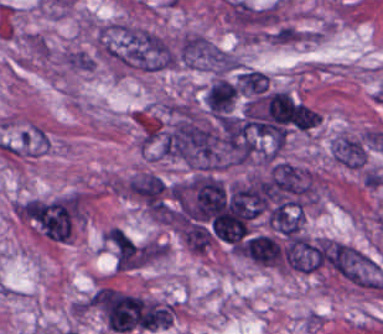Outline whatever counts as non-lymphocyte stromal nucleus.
<instances>
[{
	"label": "non-lymphocyte stromal nucleus",
	"instance_id": "a72fc3eb",
	"mask_svg": "<svg viewBox=\"0 0 383 334\" xmlns=\"http://www.w3.org/2000/svg\"><path fill=\"white\" fill-rule=\"evenodd\" d=\"M323 250L328 268L350 284L381 288L383 276L376 262L356 246L326 238Z\"/></svg>",
	"mask_w": 383,
	"mask_h": 334
},
{
	"label": "non-lymphocyte stromal nucleus",
	"instance_id": "fc2b8d12",
	"mask_svg": "<svg viewBox=\"0 0 383 334\" xmlns=\"http://www.w3.org/2000/svg\"><path fill=\"white\" fill-rule=\"evenodd\" d=\"M66 67L76 71H90L94 66V57L84 51L71 50L64 55Z\"/></svg>",
	"mask_w": 383,
	"mask_h": 334
},
{
	"label": "non-lymphocyte stromal nucleus",
	"instance_id": "3746e769",
	"mask_svg": "<svg viewBox=\"0 0 383 334\" xmlns=\"http://www.w3.org/2000/svg\"><path fill=\"white\" fill-rule=\"evenodd\" d=\"M214 57L213 42L195 32H188L174 47L173 61L184 67H210Z\"/></svg>",
	"mask_w": 383,
	"mask_h": 334
},
{
	"label": "non-lymphocyte stromal nucleus",
	"instance_id": "dd21d789",
	"mask_svg": "<svg viewBox=\"0 0 383 334\" xmlns=\"http://www.w3.org/2000/svg\"><path fill=\"white\" fill-rule=\"evenodd\" d=\"M97 43L107 61L119 68L157 71L174 64L172 49L164 38L138 26L101 24Z\"/></svg>",
	"mask_w": 383,
	"mask_h": 334
}]
</instances>
